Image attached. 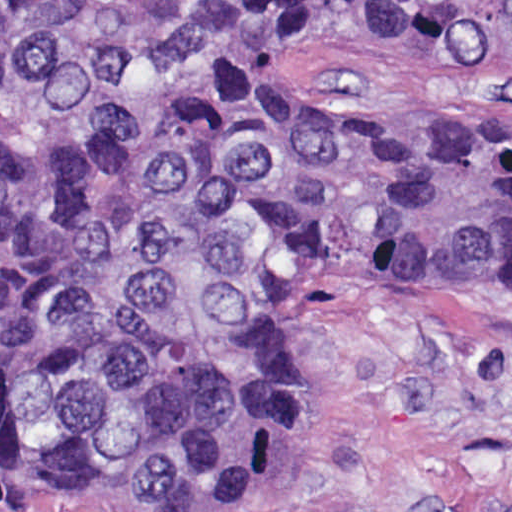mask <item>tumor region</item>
<instances>
[{
    "instance_id": "obj_1",
    "label": "tumor region",
    "mask_w": 512,
    "mask_h": 512,
    "mask_svg": "<svg viewBox=\"0 0 512 512\" xmlns=\"http://www.w3.org/2000/svg\"><path fill=\"white\" fill-rule=\"evenodd\" d=\"M512 55V0H0V498L220 506L332 287H512V116L362 123L337 18Z\"/></svg>"
}]
</instances>
